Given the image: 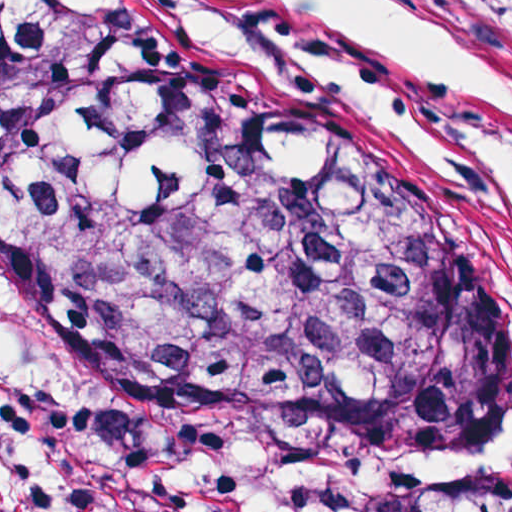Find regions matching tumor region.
Masks as SVG:
<instances>
[{
	"label": "tumor region",
	"instance_id": "tumor-region-1",
	"mask_svg": "<svg viewBox=\"0 0 512 512\" xmlns=\"http://www.w3.org/2000/svg\"><path fill=\"white\" fill-rule=\"evenodd\" d=\"M0 309L39 351L365 444L512 428L404 170L309 92L99 0H0ZM127 512H512V470L126 430Z\"/></svg>",
	"mask_w": 512,
	"mask_h": 512
}]
</instances>
